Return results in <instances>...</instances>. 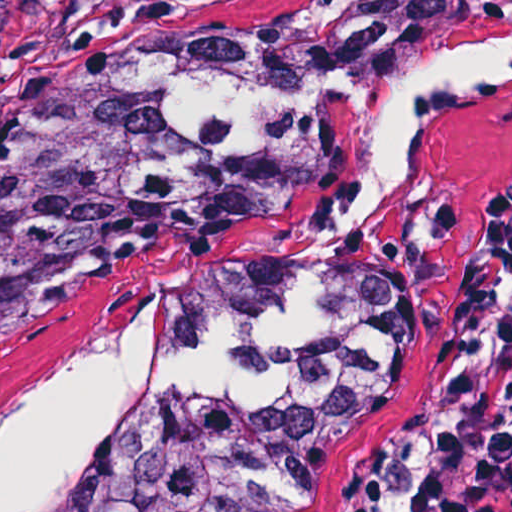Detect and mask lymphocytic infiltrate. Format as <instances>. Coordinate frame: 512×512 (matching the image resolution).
Wrapping results in <instances>:
<instances>
[{
	"mask_svg": "<svg viewBox=\"0 0 512 512\" xmlns=\"http://www.w3.org/2000/svg\"><path fill=\"white\" fill-rule=\"evenodd\" d=\"M454 346L465 412L430 459L413 512H512V184L487 211Z\"/></svg>",
	"mask_w": 512,
	"mask_h": 512,
	"instance_id": "1",
	"label": "lymphocytic infiltrate"
}]
</instances>
